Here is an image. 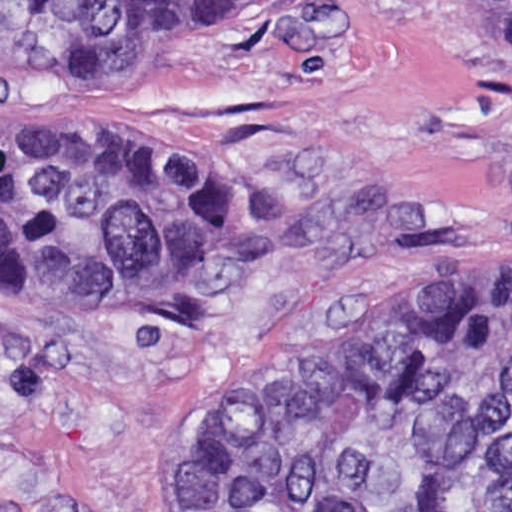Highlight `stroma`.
<instances>
[{
    "mask_svg": "<svg viewBox=\"0 0 512 512\" xmlns=\"http://www.w3.org/2000/svg\"><path fill=\"white\" fill-rule=\"evenodd\" d=\"M0 116L204 136L317 209L217 332L0 287V512H225L209 426L454 307L512 244V69L446 0H207L153 74L0 55Z\"/></svg>",
    "mask_w": 512,
    "mask_h": 512,
    "instance_id": "obj_1",
    "label": "stroma"
}]
</instances>
